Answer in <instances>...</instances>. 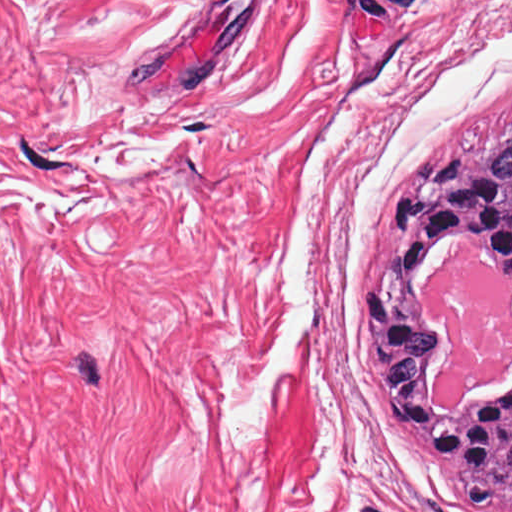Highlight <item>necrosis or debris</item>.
I'll return each instance as SVG.
<instances>
[{
    "label": "necrosis or debris",
    "instance_id": "4bbe7bcc",
    "mask_svg": "<svg viewBox=\"0 0 512 512\" xmlns=\"http://www.w3.org/2000/svg\"><path fill=\"white\" fill-rule=\"evenodd\" d=\"M444 326L450 352L433 382L434 408H460L479 387L512 373V286L481 265L474 242L454 245L419 292Z\"/></svg>",
    "mask_w": 512,
    "mask_h": 512
}]
</instances>
